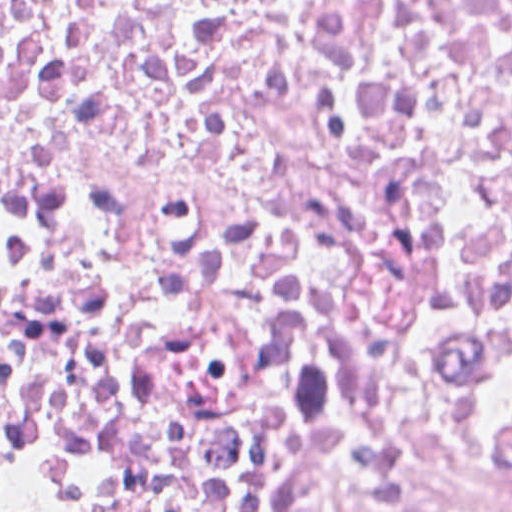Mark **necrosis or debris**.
<instances>
[{
	"label": "necrosis or debris",
	"instance_id": "4bbe7bcc",
	"mask_svg": "<svg viewBox=\"0 0 512 512\" xmlns=\"http://www.w3.org/2000/svg\"><path fill=\"white\" fill-rule=\"evenodd\" d=\"M0 504L512 512V0H0Z\"/></svg>",
	"mask_w": 512,
	"mask_h": 512
}]
</instances>
